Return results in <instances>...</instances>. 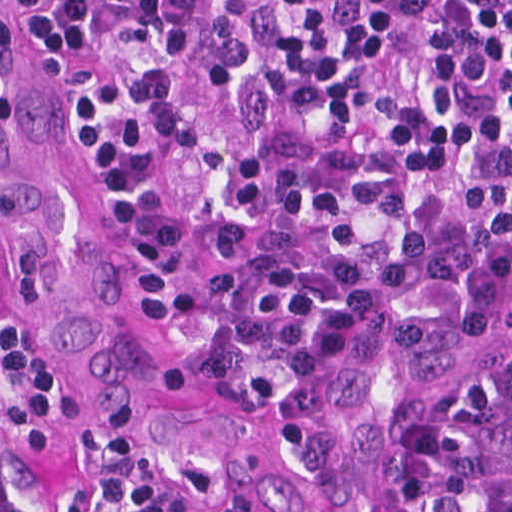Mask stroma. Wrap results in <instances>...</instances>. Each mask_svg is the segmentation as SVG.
<instances>
[{
    "instance_id": "obj_1",
    "label": "stroma",
    "mask_w": 512,
    "mask_h": 512,
    "mask_svg": "<svg viewBox=\"0 0 512 512\" xmlns=\"http://www.w3.org/2000/svg\"><path fill=\"white\" fill-rule=\"evenodd\" d=\"M0 251L38 318L1 218ZM510 350L512 268L409 299L307 372L259 383L286 437V479L274 499L227 507L234 512H374L382 458L406 432L436 414L455 384ZM112 436L118 435L76 385L73 433L32 444L24 464L0 438L1 498L52 503L83 491L100 473L102 442Z\"/></svg>"
}]
</instances>
